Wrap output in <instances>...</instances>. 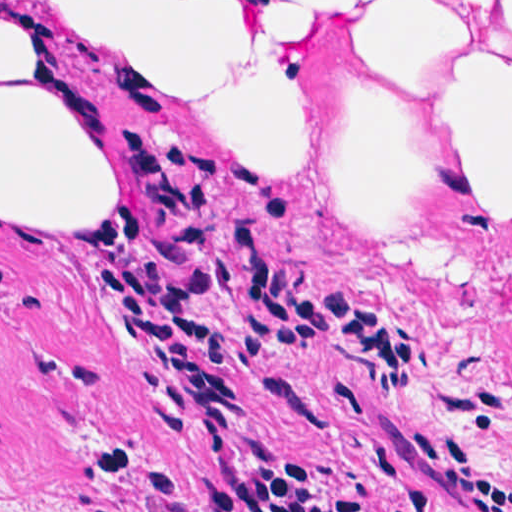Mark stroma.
I'll return each mask as SVG.
<instances>
[{
  "label": "stroma",
  "instance_id": "stroma-1",
  "mask_svg": "<svg viewBox=\"0 0 512 512\" xmlns=\"http://www.w3.org/2000/svg\"><path fill=\"white\" fill-rule=\"evenodd\" d=\"M39 1L51 75L91 105L123 203L152 153L225 155L290 203L222 194L225 259L259 225L272 267L318 278L420 344L393 395L331 350L254 357L246 307L146 216L175 292L251 408L241 466L291 455L365 512H467L405 438L475 431L512 476V0ZM217 119L225 123H217ZM100 232V231H99ZM0 229V512H149L161 470L203 501L199 431L176 440L123 356L118 255ZM111 441L129 449L124 466Z\"/></svg>",
  "mask_w": 512,
  "mask_h": 512
}]
</instances>
